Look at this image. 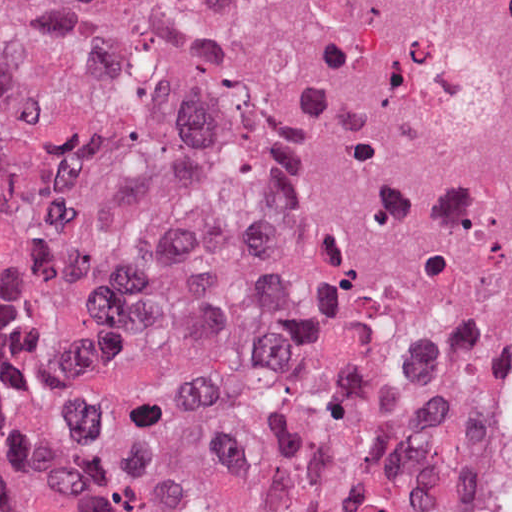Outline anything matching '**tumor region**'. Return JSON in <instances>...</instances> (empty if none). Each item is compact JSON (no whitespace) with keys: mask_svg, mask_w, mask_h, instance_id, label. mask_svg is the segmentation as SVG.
Returning a JSON list of instances; mask_svg holds the SVG:
<instances>
[{"mask_svg":"<svg viewBox=\"0 0 512 512\" xmlns=\"http://www.w3.org/2000/svg\"><path fill=\"white\" fill-rule=\"evenodd\" d=\"M0 512H512L473 416L275 279L104 0H0Z\"/></svg>","mask_w":512,"mask_h":512,"instance_id":"obj_1","label":"tumor region"}]
</instances>
